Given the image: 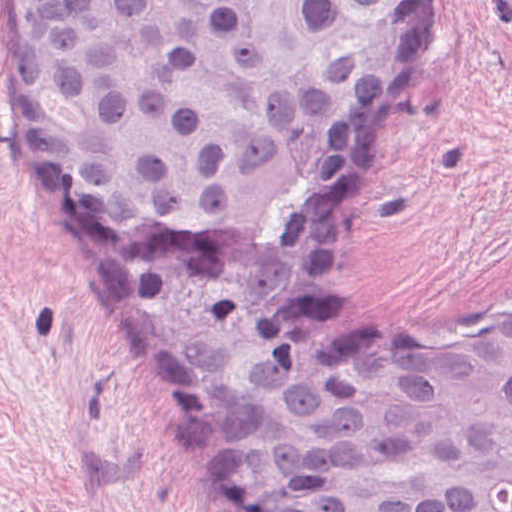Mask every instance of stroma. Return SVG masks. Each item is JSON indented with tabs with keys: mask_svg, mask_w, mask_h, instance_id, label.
<instances>
[{
	"mask_svg": "<svg viewBox=\"0 0 512 512\" xmlns=\"http://www.w3.org/2000/svg\"><path fill=\"white\" fill-rule=\"evenodd\" d=\"M361 318L453 339L512 318V0H415L412 69L332 200ZM0 512H230L133 337L0 0Z\"/></svg>",
	"mask_w": 512,
	"mask_h": 512,
	"instance_id": "obj_1",
	"label": "stroma"
}]
</instances>
